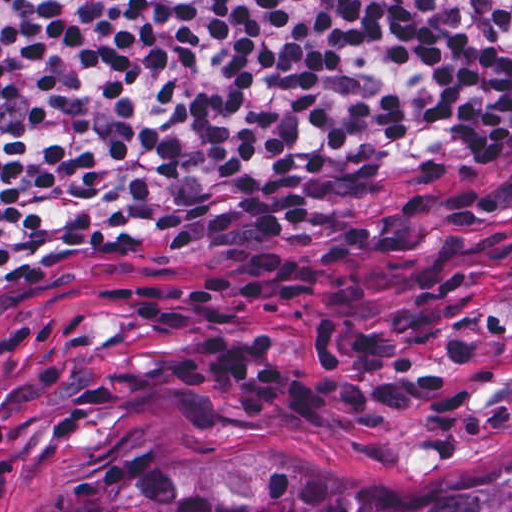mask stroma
<instances>
[{
  "label": "stroma",
  "mask_w": 512,
  "mask_h": 512,
  "mask_svg": "<svg viewBox=\"0 0 512 512\" xmlns=\"http://www.w3.org/2000/svg\"><path fill=\"white\" fill-rule=\"evenodd\" d=\"M277 242L163 239L60 256L0 280V512H39L205 450H296L384 476L512 461V133L314 191ZM266 297L236 331L279 341L328 395L247 420L226 385L177 389L197 328L151 330L98 301L113 278L182 302L219 278Z\"/></svg>",
  "instance_id": "stroma-1"
}]
</instances>
